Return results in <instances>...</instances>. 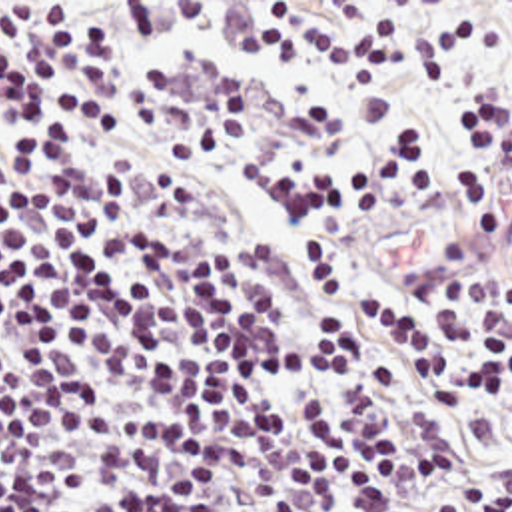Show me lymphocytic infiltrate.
Segmentation results:
<instances>
[{"instance_id": "f902f5d3", "label": "lymphocytic infiltrate", "mask_w": 512, "mask_h": 512, "mask_svg": "<svg viewBox=\"0 0 512 512\" xmlns=\"http://www.w3.org/2000/svg\"><path fill=\"white\" fill-rule=\"evenodd\" d=\"M0 192V512H512L498 140ZM486 214L336 275L354 218Z\"/></svg>"}]
</instances>
